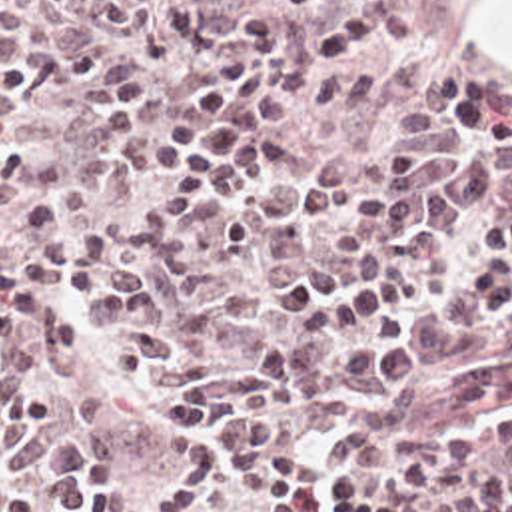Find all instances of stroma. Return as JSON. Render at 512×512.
I'll use <instances>...</instances> for the list:
<instances>
[{
	"instance_id": "obj_1",
	"label": "stroma",
	"mask_w": 512,
	"mask_h": 512,
	"mask_svg": "<svg viewBox=\"0 0 512 512\" xmlns=\"http://www.w3.org/2000/svg\"><path fill=\"white\" fill-rule=\"evenodd\" d=\"M464 15L472 49L486 73L512 85V0H444Z\"/></svg>"
}]
</instances>
